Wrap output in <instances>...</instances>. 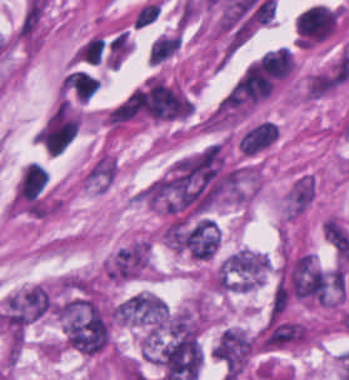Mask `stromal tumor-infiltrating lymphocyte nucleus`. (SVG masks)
Masks as SVG:
<instances>
[{
    "label": "stromal tumor-infiltrating lymphocyte nucleus",
    "mask_w": 349,
    "mask_h": 380,
    "mask_svg": "<svg viewBox=\"0 0 349 380\" xmlns=\"http://www.w3.org/2000/svg\"><path fill=\"white\" fill-rule=\"evenodd\" d=\"M66 84L78 102L86 103L100 86L92 74L80 71L69 73Z\"/></svg>",
    "instance_id": "1"
},
{
    "label": "stromal tumor-infiltrating lymphocyte nucleus",
    "mask_w": 349,
    "mask_h": 380,
    "mask_svg": "<svg viewBox=\"0 0 349 380\" xmlns=\"http://www.w3.org/2000/svg\"><path fill=\"white\" fill-rule=\"evenodd\" d=\"M180 42L181 34H179L178 32L161 34L149 47V63L157 64L165 58L174 54Z\"/></svg>",
    "instance_id": "2"
},
{
    "label": "stromal tumor-infiltrating lymphocyte nucleus",
    "mask_w": 349,
    "mask_h": 380,
    "mask_svg": "<svg viewBox=\"0 0 349 380\" xmlns=\"http://www.w3.org/2000/svg\"><path fill=\"white\" fill-rule=\"evenodd\" d=\"M160 12V3L149 2L142 6L133 20L134 28H142L145 25L153 22Z\"/></svg>",
    "instance_id": "3"
}]
</instances>
